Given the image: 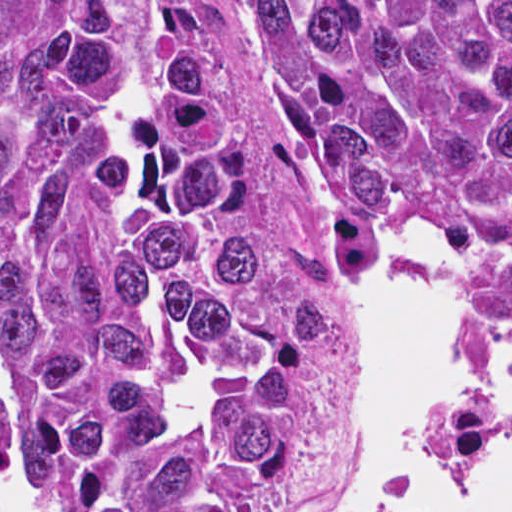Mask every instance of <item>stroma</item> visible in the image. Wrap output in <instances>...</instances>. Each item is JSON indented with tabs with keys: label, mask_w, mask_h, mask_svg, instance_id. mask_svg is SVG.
<instances>
[{
	"label": "stroma",
	"mask_w": 512,
	"mask_h": 512,
	"mask_svg": "<svg viewBox=\"0 0 512 512\" xmlns=\"http://www.w3.org/2000/svg\"><path fill=\"white\" fill-rule=\"evenodd\" d=\"M170 2L219 94L243 180L335 341L331 394L311 449L275 511L332 512L342 477L351 349L363 320V291L319 147L253 0Z\"/></svg>",
	"instance_id": "35a3bbf8"
}]
</instances>
